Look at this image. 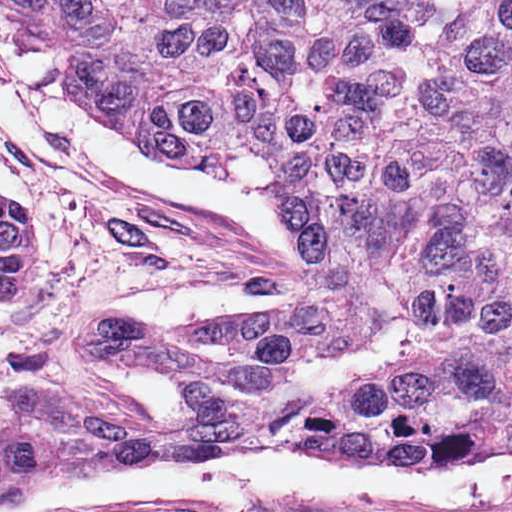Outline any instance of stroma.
I'll list each match as a JSON object with an SVG mask.
<instances>
[{
    "mask_svg": "<svg viewBox=\"0 0 512 512\" xmlns=\"http://www.w3.org/2000/svg\"><path fill=\"white\" fill-rule=\"evenodd\" d=\"M0 35L16 37L3 0ZM0 148L34 192L43 260L36 288L0 299V430L171 416L186 405V384L89 357L75 346L83 325L184 333L304 287V245L273 195L213 170L255 186L278 208L305 275L241 230L194 206L150 199L69 148L32 110L1 53Z\"/></svg>",
    "mask_w": 512,
    "mask_h": 512,
    "instance_id": "stroma-1",
    "label": "stroma"
}]
</instances>
